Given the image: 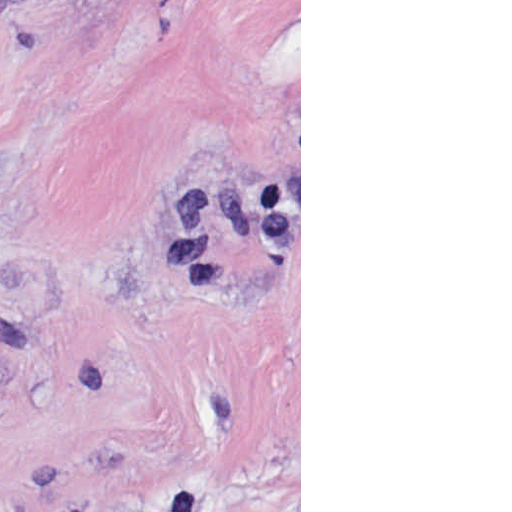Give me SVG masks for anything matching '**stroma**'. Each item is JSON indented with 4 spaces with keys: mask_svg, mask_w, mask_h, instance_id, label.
Listing matches in <instances>:
<instances>
[{
    "mask_svg": "<svg viewBox=\"0 0 512 512\" xmlns=\"http://www.w3.org/2000/svg\"><path fill=\"white\" fill-rule=\"evenodd\" d=\"M0 512H301V0H0Z\"/></svg>",
    "mask_w": 512,
    "mask_h": 512,
    "instance_id": "obj_1",
    "label": "stroma"
}]
</instances>
